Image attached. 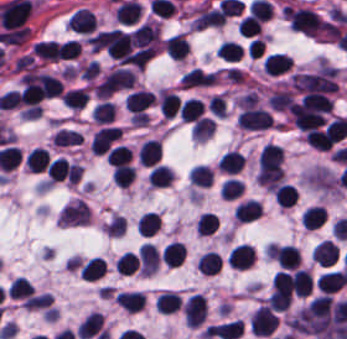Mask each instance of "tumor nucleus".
<instances>
[{
    "mask_svg": "<svg viewBox=\"0 0 347 339\" xmlns=\"http://www.w3.org/2000/svg\"><path fill=\"white\" fill-rule=\"evenodd\" d=\"M116 40V29L97 31L89 36L87 42L89 49L93 52L108 53L110 52Z\"/></svg>",
    "mask_w": 347,
    "mask_h": 339,
    "instance_id": "obj_1",
    "label": "tumor nucleus"
}]
</instances>
